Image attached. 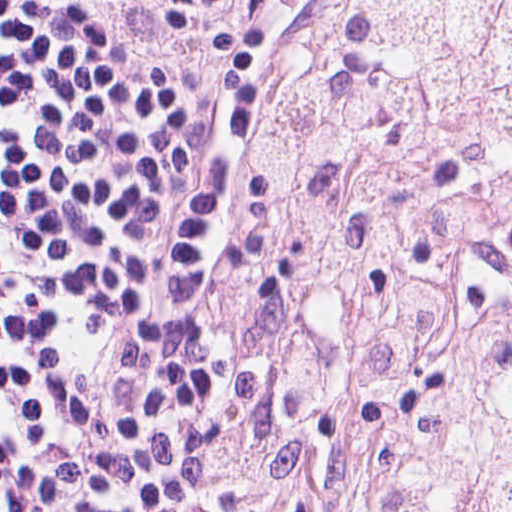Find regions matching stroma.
<instances>
[{"label": "stroma", "mask_w": 512, "mask_h": 512, "mask_svg": "<svg viewBox=\"0 0 512 512\" xmlns=\"http://www.w3.org/2000/svg\"><path fill=\"white\" fill-rule=\"evenodd\" d=\"M113 54L163 96H216L229 121V199L200 286L231 362V435L220 512H277L249 383L260 263L263 150L283 80L315 40L328 0H64Z\"/></svg>", "instance_id": "1"}]
</instances>
